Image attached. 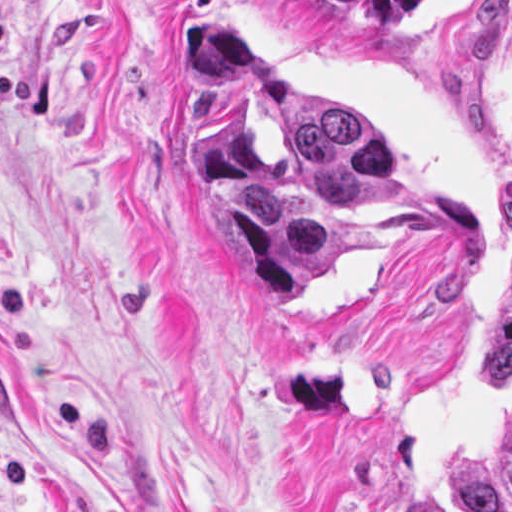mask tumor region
<instances>
[{
	"mask_svg": "<svg viewBox=\"0 0 512 512\" xmlns=\"http://www.w3.org/2000/svg\"><path fill=\"white\" fill-rule=\"evenodd\" d=\"M375 31H406L434 0H298ZM182 68L226 98V115L189 134L192 168L233 219L273 307L303 302L340 264L370 249L355 210L393 196L390 159L358 123L286 78L239 28L197 4L180 21ZM477 360L512 385V262L477 313ZM458 512H512V418L472 462L440 473Z\"/></svg>",
	"mask_w": 512,
	"mask_h": 512,
	"instance_id": "tumor-region-1",
	"label": "tumor region"
}]
</instances>
